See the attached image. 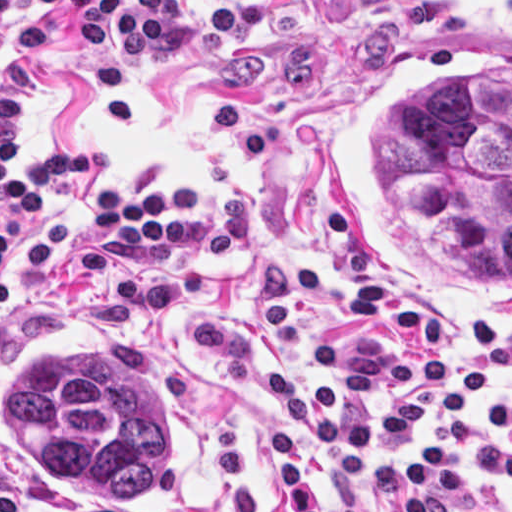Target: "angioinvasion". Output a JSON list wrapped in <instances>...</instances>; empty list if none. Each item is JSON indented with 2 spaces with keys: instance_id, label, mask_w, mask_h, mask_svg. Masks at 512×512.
<instances>
[{
  "instance_id": "1",
  "label": "angioinvasion",
  "mask_w": 512,
  "mask_h": 512,
  "mask_svg": "<svg viewBox=\"0 0 512 512\" xmlns=\"http://www.w3.org/2000/svg\"><path fill=\"white\" fill-rule=\"evenodd\" d=\"M404 36L344 102L331 234L382 305L512 324V0H368Z\"/></svg>"
}]
</instances>
